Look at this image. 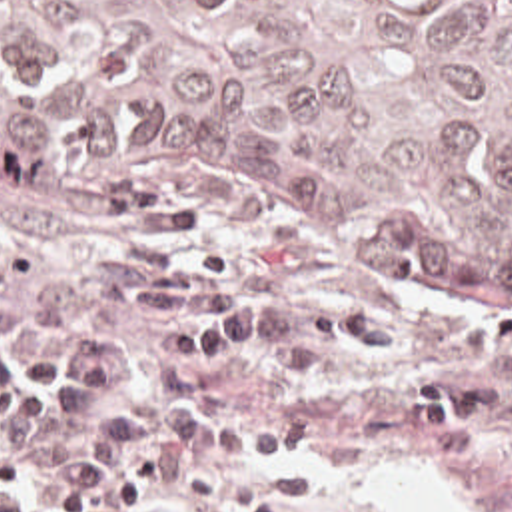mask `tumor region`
I'll use <instances>...</instances> for the list:
<instances>
[{
    "instance_id": "e687c5a6",
    "label": "tumor region",
    "mask_w": 512,
    "mask_h": 512,
    "mask_svg": "<svg viewBox=\"0 0 512 512\" xmlns=\"http://www.w3.org/2000/svg\"><path fill=\"white\" fill-rule=\"evenodd\" d=\"M0 175L512 309V0H0Z\"/></svg>"
}]
</instances>
